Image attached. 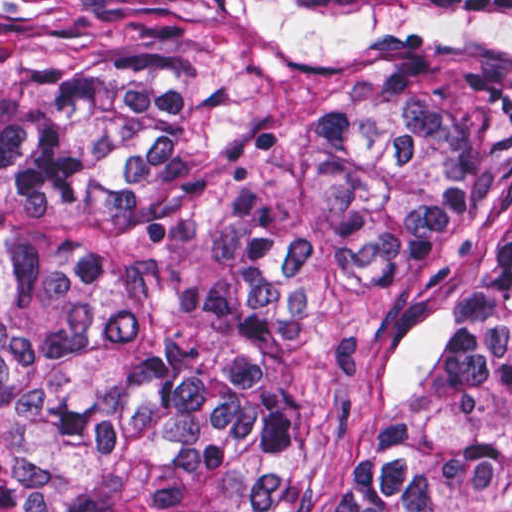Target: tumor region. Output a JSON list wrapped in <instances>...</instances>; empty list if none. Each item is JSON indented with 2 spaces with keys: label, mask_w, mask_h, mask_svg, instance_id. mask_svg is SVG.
Here are the masks:
<instances>
[{
  "label": "tumor region",
  "mask_w": 512,
  "mask_h": 512,
  "mask_svg": "<svg viewBox=\"0 0 512 512\" xmlns=\"http://www.w3.org/2000/svg\"><path fill=\"white\" fill-rule=\"evenodd\" d=\"M512 490V0H0V512Z\"/></svg>",
  "instance_id": "e687c5a6"
}]
</instances>
